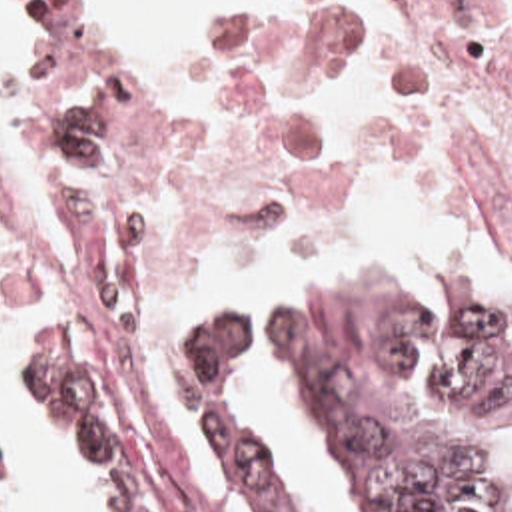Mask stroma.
I'll return each instance as SVG.
<instances>
[{
    "instance_id": "obj_1",
    "label": "stroma",
    "mask_w": 512,
    "mask_h": 512,
    "mask_svg": "<svg viewBox=\"0 0 512 512\" xmlns=\"http://www.w3.org/2000/svg\"><path fill=\"white\" fill-rule=\"evenodd\" d=\"M12 2L30 52L32 130L44 194L34 208H26L0 168V212L10 220L48 232H58V224L52 202L46 86L34 60L46 26L76 52L90 76H214L272 42L296 4V0H258L224 24L208 30L198 46L176 64L116 68L92 30L86 0ZM310 278H410L426 286L482 292L512 310V288L500 274H424L366 262H280L250 274L234 304L222 312L244 324L248 352L268 344V308L276 292ZM74 320H80L78 344L82 360L106 415L132 449L140 493L152 512H218L206 483L202 459L170 395V360L176 338L136 344L96 298ZM20 336L22 332H0V344L14 350ZM248 417L254 419L250 411ZM52 429L68 451L74 475L96 503L98 512H102V483L98 475L74 455L68 439L54 425ZM0 453L6 512L14 499V451L2 423Z\"/></svg>"
}]
</instances>
